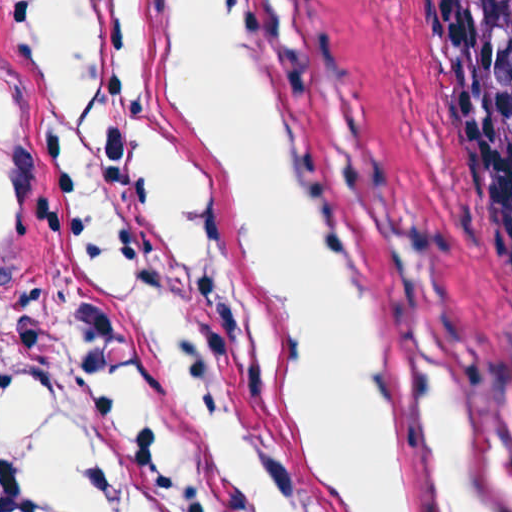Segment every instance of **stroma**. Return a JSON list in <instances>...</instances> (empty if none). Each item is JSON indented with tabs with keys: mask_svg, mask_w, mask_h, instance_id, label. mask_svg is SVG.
I'll return each mask as SVG.
<instances>
[{
	"mask_svg": "<svg viewBox=\"0 0 512 512\" xmlns=\"http://www.w3.org/2000/svg\"><path fill=\"white\" fill-rule=\"evenodd\" d=\"M43 1L0 0V410L4 360L71 218L28 155L9 96L20 29ZM245 2L318 174L385 280L463 357L512 478V129L459 0ZM139 273L216 398L293 430L243 344ZM302 457L319 512H337Z\"/></svg>",
	"mask_w": 512,
	"mask_h": 512,
	"instance_id": "1",
	"label": "stroma"
}]
</instances>
